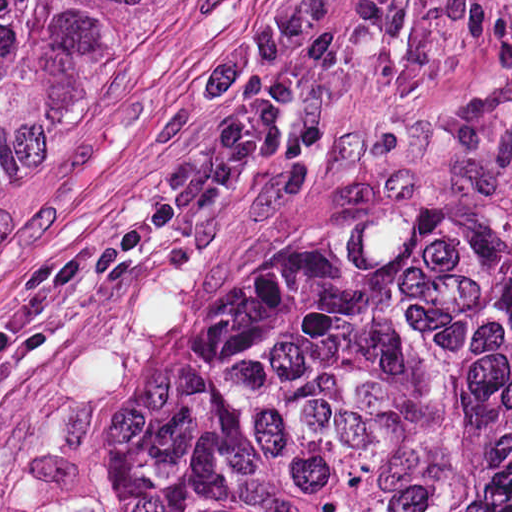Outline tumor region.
I'll use <instances>...</instances> for the list:
<instances>
[{
    "label": "tumor region",
    "mask_w": 512,
    "mask_h": 512,
    "mask_svg": "<svg viewBox=\"0 0 512 512\" xmlns=\"http://www.w3.org/2000/svg\"><path fill=\"white\" fill-rule=\"evenodd\" d=\"M155 0H0V140ZM59 512H512V240L472 204L226 264Z\"/></svg>",
    "instance_id": "obj_1"
}]
</instances>
